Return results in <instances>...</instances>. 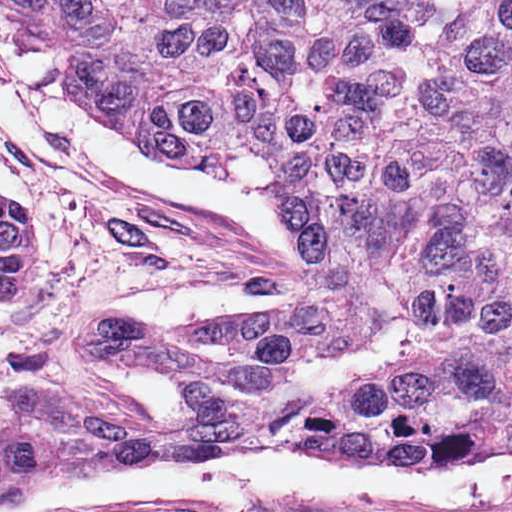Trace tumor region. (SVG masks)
I'll list each match as a JSON object with an SVG mask.
<instances>
[{"instance_id":"e687c5a6","label":"tumor region","mask_w":512,"mask_h":512,"mask_svg":"<svg viewBox=\"0 0 512 512\" xmlns=\"http://www.w3.org/2000/svg\"><path fill=\"white\" fill-rule=\"evenodd\" d=\"M138 139L275 197L304 287L184 333L83 325L168 373L153 420L0 430V497L86 464L320 437L512 458V0H3ZM37 223L0 198V299Z\"/></svg>"}]
</instances>
